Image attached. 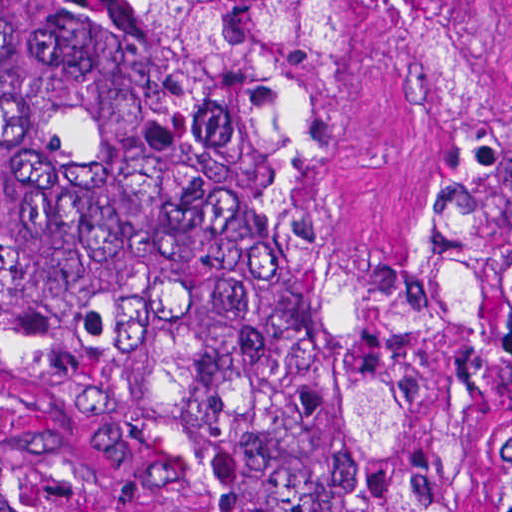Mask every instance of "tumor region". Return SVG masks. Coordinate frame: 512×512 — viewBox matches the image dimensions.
<instances>
[{"mask_svg":"<svg viewBox=\"0 0 512 512\" xmlns=\"http://www.w3.org/2000/svg\"><path fill=\"white\" fill-rule=\"evenodd\" d=\"M419 1H0V401L211 512H512V113L405 251L323 196V99Z\"/></svg>","mask_w":512,"mask_h":512,"instance_id":"tumor-region-1","label":"tumor region"}]
</instances>
